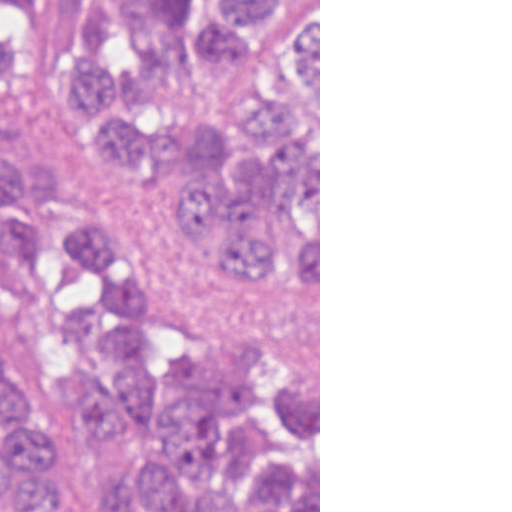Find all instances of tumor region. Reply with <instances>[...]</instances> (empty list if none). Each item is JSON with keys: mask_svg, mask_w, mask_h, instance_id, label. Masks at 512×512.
<instances>
[{"mask_svg": "<svg viewBox=\"0 0 512 512\" xmlns=\"http://www.w3.org/2000/svg\"><path fill=\"white\" fill-rule=\"evenodd\" d=\"M35 80L163 220L319 304V0H0ZM0 512H319V369L282 325L176 304L57 167L0 163Z\"/></svg>", "mask_w": 512, "mask_h": 512, "instance_id": "tumor-region-1", "label": "tumor region"}]
</instances>
